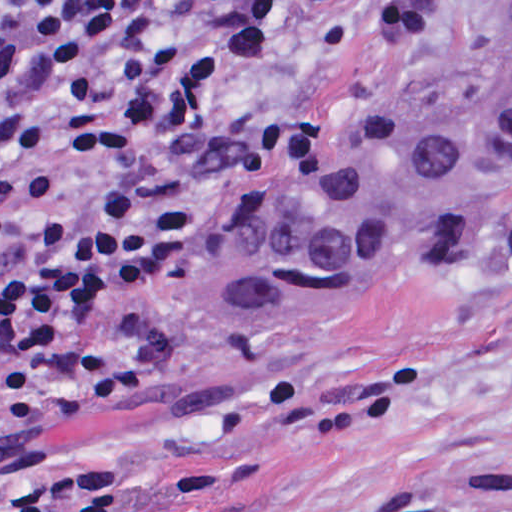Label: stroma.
Instances as JSON below:
<instances>
[{
  "mask_svg": "<svg viewBox=\"0 0 512 512\" xmlns=\"http://www.w3.org/2000/svg\"><path fill=\"white\" fill-rule=\"evenodd\" d=\"M511 19L512 0L344 5L309 76L345 93L332 138L125 310L122 393L47 432L56 476L104 512H512V152L471 213L351 292L228 349L193 329L194 261L339 171L432 71ZM102 307L41 359L30 422L0 431V500L34 488L39 425L71 401Z\"/></svg>",
  "mask_w": 512,
  "mask_h": 512,
  "instance_id": "1",
  "label": "stroma"
}]
</instances>
